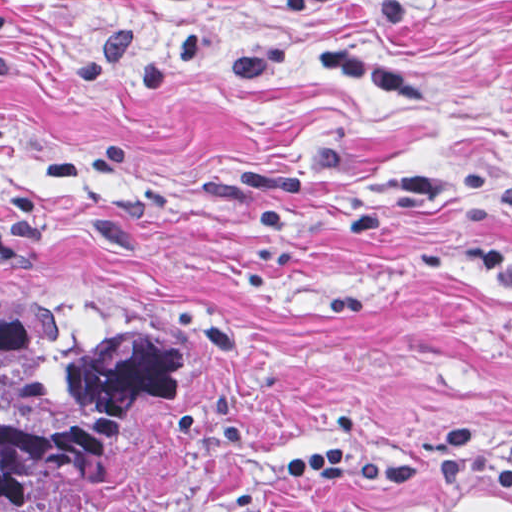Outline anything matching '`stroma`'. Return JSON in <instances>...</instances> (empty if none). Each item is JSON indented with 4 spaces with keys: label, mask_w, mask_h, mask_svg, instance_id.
Listing matches in <instances>:
<instances>
[{
    "label": "stroma",
    "mask_w": 512,
    "mask_h": 512,
    "mask_svg": "<svg viewBox=\"0 0 512 512\" xmlns=\"http://www.w3.org/2000/svg\"><path fill=\"white\" fill-rule=\"evenodd\" d=\"M0 309L207 337L78 512H512L283 481L447 433L512 466V0H0Z\"/></svg>",
    "instance_id": "stroma-1"
}]
</instances>
